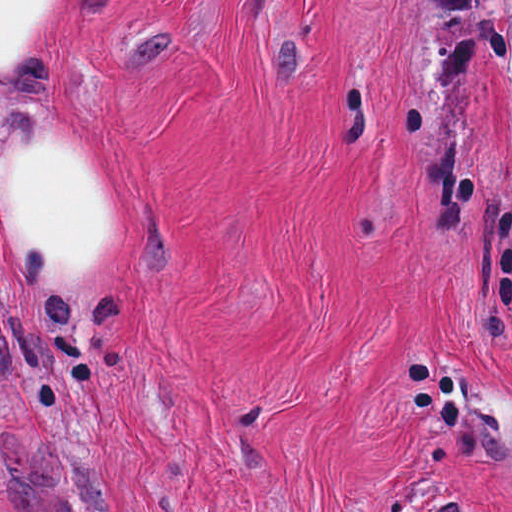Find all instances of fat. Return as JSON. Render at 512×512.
<instances>
[{"mask_svg": "<svg viewBox=\"0 0 512 512\" xmlns=\"http://www.w3.org/2000/svg\"><path fill=\"white\" fill-rule=\"evenodd\" d=\"M73 1L0 0V280L18 303L70 301L121 254L110 199L30 121V83Z\"/></svg>", "mask_w": 512, "mask_h": 512, "instance_id": "obj_1", "label": "fat"}]
</instances>
